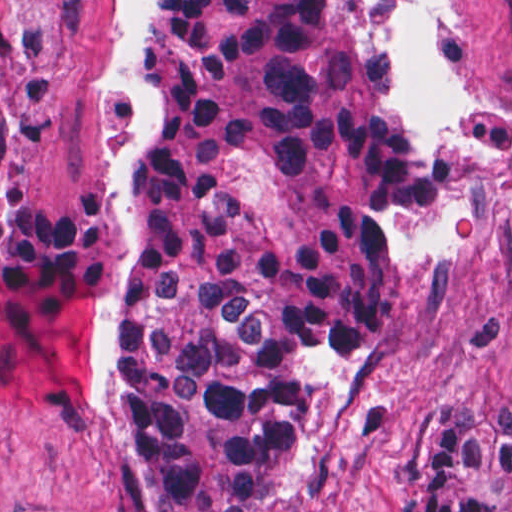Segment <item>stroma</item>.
Instances as JSON below:
<instances>
[{
	"label": "stroma",
	"instance_id": "stroma-1",
	"mask_svg": "<svg viewBox=\"0 0 512 512\" xmlns=\"http://www.w3.org/2000/svg\"><path fill=\"white\" fill-rule=\"evenodd\" d=\"M150 31L151 0H0V512H171L111 433L136 312L120 198L160 127ZM391 65L435 198L398 218L389 323L317 361L268 512H402L425 398L512 415V0H391Z\"/></svg>",
	"mask_w": 512,
	"mask_h": 512
}]
</instances>
